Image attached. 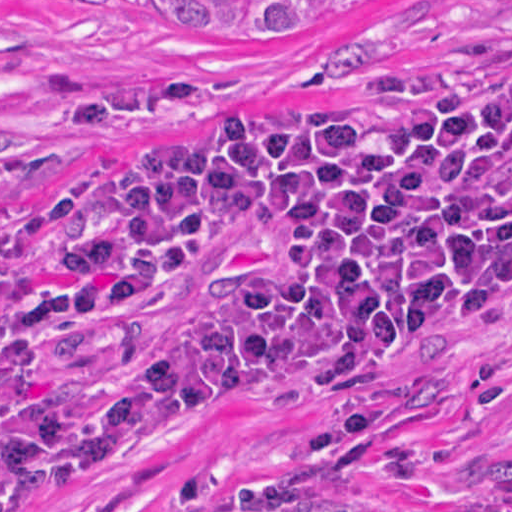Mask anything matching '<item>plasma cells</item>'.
<instances>
[{"instance_id": "9512152a", "label": "plasma cells", "mask_w": 512, "mask_h": 512, "mask_svg": "<svg viewBox=\"0 0 512 512\" xmlns=\"http://www.w3.org/2000/svg\"><path fill=\"white\" fill-rule=\"evenodd\" d=\"M507 76L249 121L182 106L133 143L109 201L57 276L0 297V357L137 308L253 240H281L278 280L171 322L97 367L0 453V512H42L199 439L271 387H349L478 347L512 316ZM23 232L0 194V276Z\"/></svg>"}]
</instances>
